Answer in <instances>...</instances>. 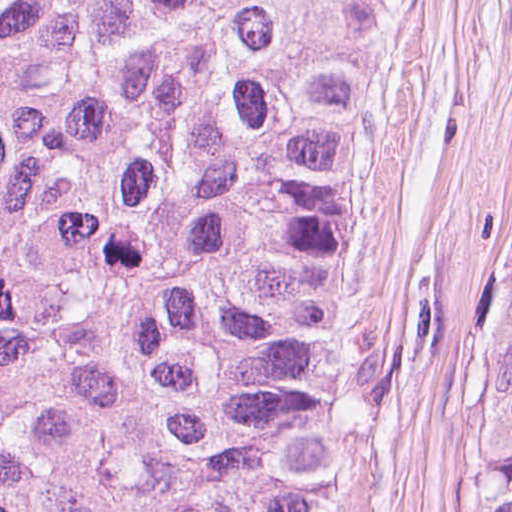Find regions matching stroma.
Here are the masks:
<instances>
[{"instance_id":"stroma-1","label":"stroma","mask_w":512,"mask_h":512,"mask_svg":"<svg viewBox=\"0 0 512 512\" xmlns=\"http://www.w3.org/2000/svg\"><path fill=\"white\" fill-rule=\"evenodd\" d=\"M511 302L512 0H371L327 313L332 512H482V387Z\"/></svg>"}]
</instances>
